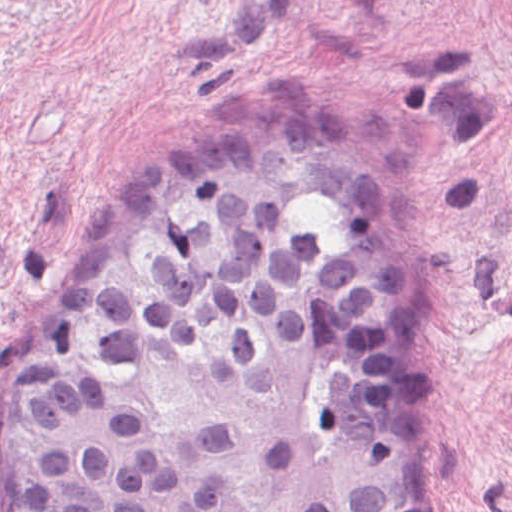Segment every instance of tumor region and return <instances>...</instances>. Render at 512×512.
<instances>
[{
	"instance_id": "1",
	"label": "tumor region",
	"mask_w": 512,
	"mask_h": 512,
	"mask_svg": "<svg viewBox=\"0 0 512 512\" xmlns=\"http://www.w3.org/2000/svg\"><path fill=\"white\" fill-rule=\"evenodd\" d=\"M301 196L393 231L390 173L308 114L142 176L4 368L5 512H415L375 284L274 218Z\"/></svg>"
}]
</instances>
